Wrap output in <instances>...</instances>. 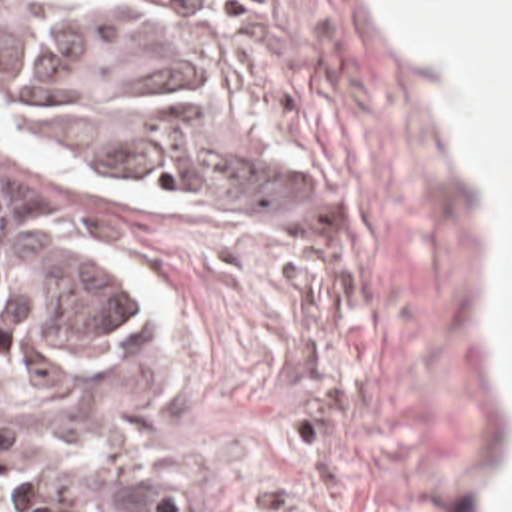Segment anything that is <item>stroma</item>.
<instances>
[{"instance_id": "35a3bbf8", "label": "stroma", "mask_w": 512, "mask_h": 512, "mask_svg": "<svg viewBox=\"0 0 512 512\" xmlns=\"http://www.w3.org/2000/svg\"><path fill=\"white\" fill-rule=\"evenodd\" d=\"M0 214L93 224L151 310L23 400L61 450L211 512L488 509L492 244L375 0H0Z\"/></svg>"}]
</instances>
